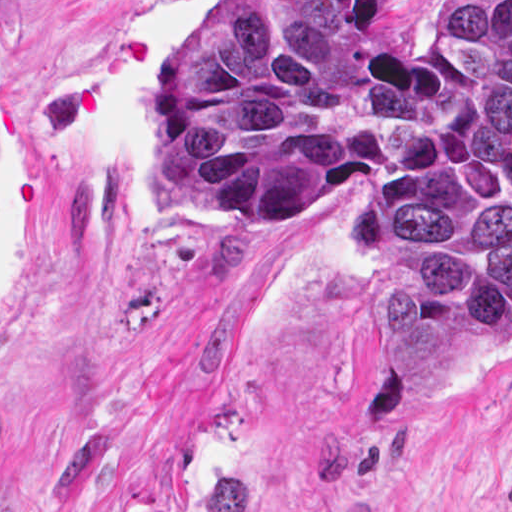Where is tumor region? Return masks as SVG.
<instances>
[{
  "mask_svg": "<svg viewBox=\"0 0 512 512\" xmlns=\"http://www.w3.org/2000/svg\"><path fill=\"white\" fill-rule=\"evenodd\" d=\"M384 57L378 1H228L184 29L156 164L215 226L257 231L369 179L362 299L448 387L512 344V1H422Z\"/></svg>",
  "mask_w": 512,
  "mask_h": 512,
  "instance_id": "obj_1",
  "label": "tumor region"
}]
</instances>
